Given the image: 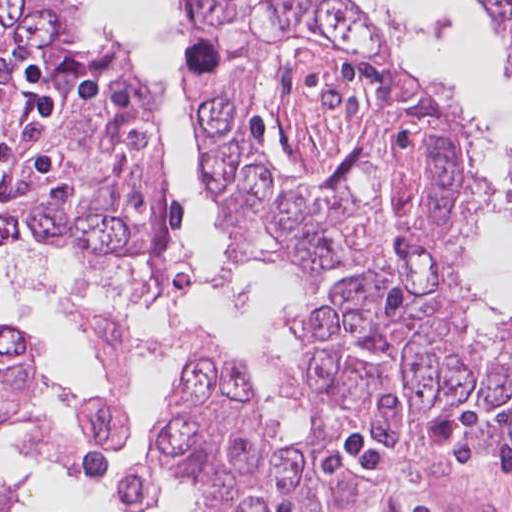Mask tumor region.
<instances>
[{"mask_svg": "<svg viewBox=\"0 0 512 512\" xmlns=\"http://www.w3.org/2000/svg\"><path fill=\"white\" fill-rule=\"evenodd\" d=\"M219 227L244 261L301 286L310 428L275 437L246 361L195 331L150 441L124 473L126 512L182 474L213 512H330L347 480L322 467L342 434L419 460L456 444L512 454V402L396 54L348 10L182 64ZM149 76L0 123V245L74 248L143 269L154 299L193 282L183 207L165 181ZM54 396L113 449L129 420L64 388L44 346L0 318V427ZM13 491L0 488V512Z\"/></svg>", "mask_w": 512, "mask_h": 512, "instance_id": "e687c5a6", "label": "tumor region"}]
</instances>
